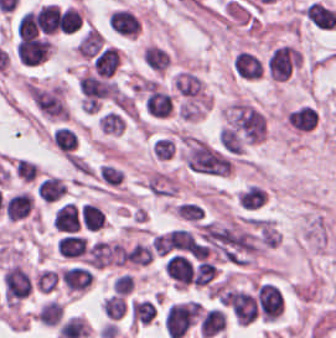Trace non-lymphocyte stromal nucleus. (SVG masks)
I'll use <instances>...</instances> for the list:
<instances>
[{"instance_id":"non-lymphocyte-stromal-nucleus-1","label":"non-lymphocyte stromal nucleus","mask_w":336,"mask_h":338,"mask_svg":"<svg viewBox=\"0 0 336 338\" xmlns=\"http://www.w3.org/2000/svg\"><path fill=\"white\" fill-rule=\"evenodd\" d=\"M183 160L194 171L207 175H226L230 163L202 139L185 138Z\"/></svg>"},{"instance_id":"non-lymphocyte-stromal-nucleus-2","label":"non-lymphocyte stromal nucleus","mask_w":336,"mask_h":338,"mask_svg":"<svg viewBox=\"0 0 336 338\" xmlns=\"http://www.w3.org/2000/svg\"><path fill=\"white\" fill-rule=\"evenodd\" d=\"M38 111L51 118L67 117V105L62 90L54 85H32L27 88Z\"/></svg>"},{"instance_id":"non-lymphocyte-stromal-nucleus-3","label":"non-lymphocyte stromal nucleus","mask_w":336,"mask_h":338,"mask_svg":"<svg viewBox=\"0 0 336 338\" xmlns=\"http://www.w3.org/2000/svg\"><path fill=\"white\" fill-rule=\"evenodd\" d=\"M38 167L36 163L28 161L24 158H17L13 160L12 175L23 180H34L37 175Z\"/></svg>"}]
</instances>
